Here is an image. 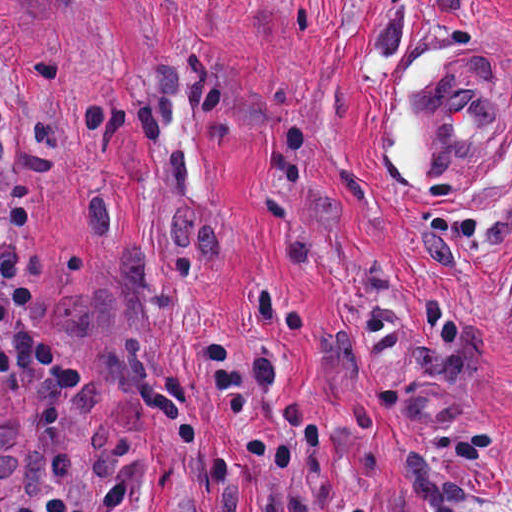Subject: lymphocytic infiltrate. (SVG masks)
Here are the masks:
<instances>
[{"instance_id":"obj_1","label":"lymphocytic infiltrate","mask_w":512,"mask_h":512,"mask_svg":"<svg viewBox=\"0 0 512 512\" xmlns=\"http://www.w3.org/2000/svg\"><path fill=\"white\" fill-rule=\"evenodd\" d=\"M6 152L0 112V155ZM30 227L28 182H16L0 195V379L15 387L40 368L60 387H78L83 371L14 241Z\"/></svg>"}]
</instances>
